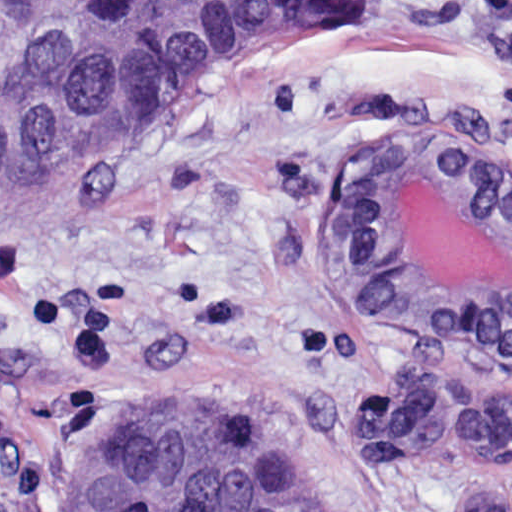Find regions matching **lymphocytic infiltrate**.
<instances>
[{
  "label": "lymphocytic infiltrate",
  "mask_w": 512,
  "mask_h": 512,
  "mask_svg": "<svg viewBox=\"0 0 512 512\" xmlns=\"http://www.w3.org/2000/svg\"><path fill=\"white\" fill-rule=\"evenodd\" d=\"M512 67V0H461Z\"/></svg>",
  "instance_id": "obj_1"
}]
</instances>
